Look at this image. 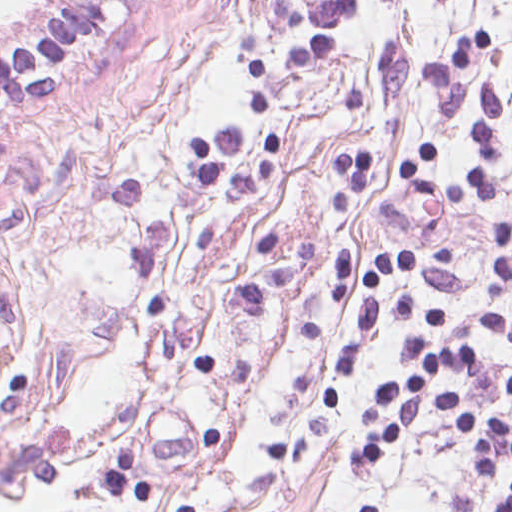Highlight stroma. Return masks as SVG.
<instances>
[{
  "instance_id": "35a3bbf8",
  "label": "stroma",
  "mask_w": 512,
  "mask_h": 512,
  "mask_svg": "<svg viewBox=\"0 0 512 512\" xmlns=\"http://www.w3.org/2000/svg\"><path fill=\"white\" fill-rule=\"evenodd\" d=\"M68 0L0 28V50ZM118 0L94 41L0 105V506L16 512H498L512 465L472 475L432 415L390 458L347 464L374 435L377 387L407 380L409 318H381L349 375L338 348L375 256L452 246L450 267L384 275L380 294L444 312L426 344L475 341L482 373L447 371L472 408L512 422V0H357L308 69L270 4ZM298 74V75H297ZM497 92L492 200L426 198L425 173L476 160L480 90ZM339 151L367 153L345 213ZM152 487L114 498L120 452Z\"/></svg>"
}]
</instances>
